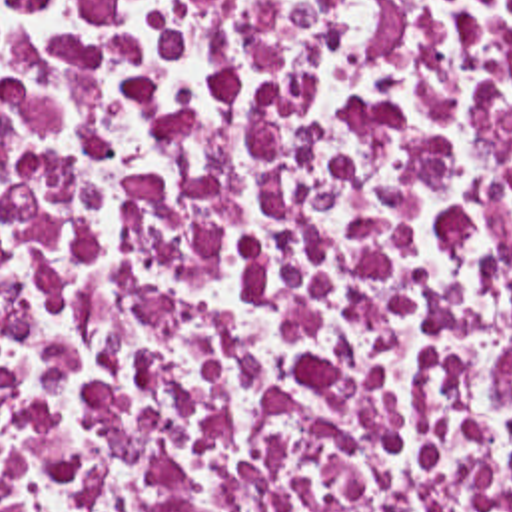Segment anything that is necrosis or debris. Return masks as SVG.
<instances>
[{
	"instance_id": "necrosis-or-debris-1",
	"label": "necrosis or debris",
	"mask_w": 512,
	"mask_h": 512,
	"mask_svg": "<svg viewBox=\"0 0 512 512\" xmlns=\"http://www.w3.org/2000/svg\"><path fill=\"white\" fill-rule=\"evenodd\" d=\"M0 512H512V0H0Z\"/></svg>"
}]
</instances>
